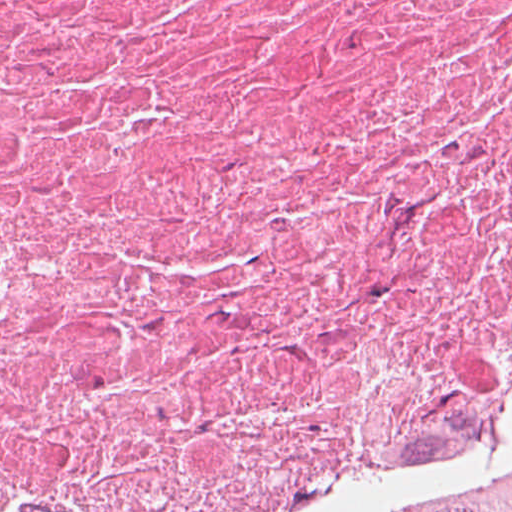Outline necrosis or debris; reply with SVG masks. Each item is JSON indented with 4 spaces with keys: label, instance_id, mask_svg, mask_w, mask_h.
<instances>
[{
    "label": "necrosis or debris",
    "instance_id": "1",
    "mask_svg": "<svg viewBox=\"0 0 512 512\" xmlns=\"http://www.w3.org/2000/svg\"><path fill=\"white\" fill-rule=\"evenodd\" d=\"M512 489V0H0V512Z\"/></svg>",
    "mask_w": 512,
    "mask_h": 512
}]
</instances>
